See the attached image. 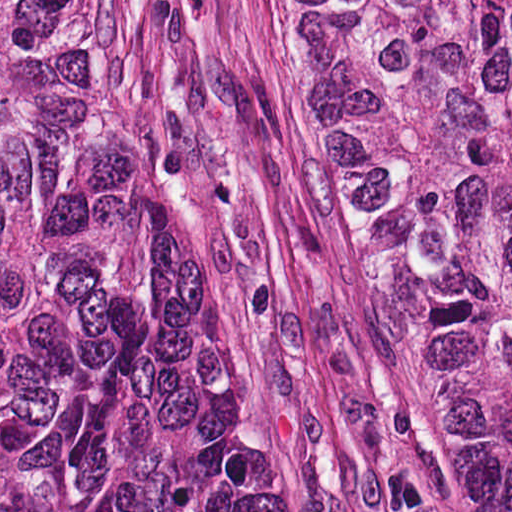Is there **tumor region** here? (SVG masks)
Instances as JSON below:
<instances>
[{"label": "tumor region", "mask_w": 512, "mask_h": 512, "mask_svg": "<svg viewBox=\"0 0 512 512\" xmlns=\"http://www.w3.org/2000/svg\"><path fill=\"white\" fill-rule=\"evenodd\" d=\"M326 197L512 512V0H298ZM0 512H309L119 0H0Z\"/></svg>", "instance_id": "e687c5a6"}]
</instances>
